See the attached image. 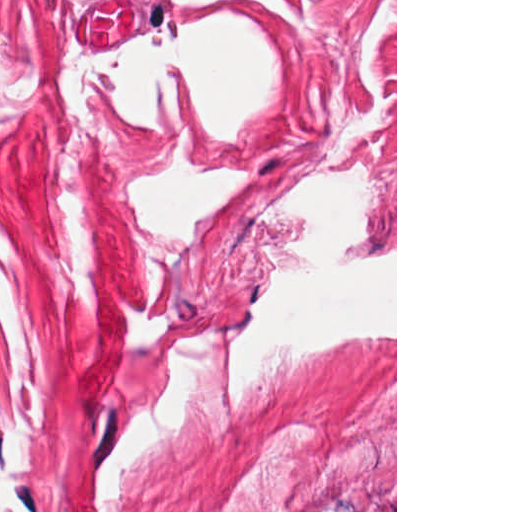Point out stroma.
<instances>
[{
  "mask_svg": "<svg viewBox=\"0 0 512 512\" xmlns=\"http://www.w3.org/2000/svg\"><path fill=\"white\" fill-rule=\"evenodd\" d=\"M397 398L0 356V512H386Z\"/></svg>",
  "mask_w": 512,
  "mask_h": 512,
  "instance_id": "obj_1",
  "label": "stroma"
}]
</instances>
